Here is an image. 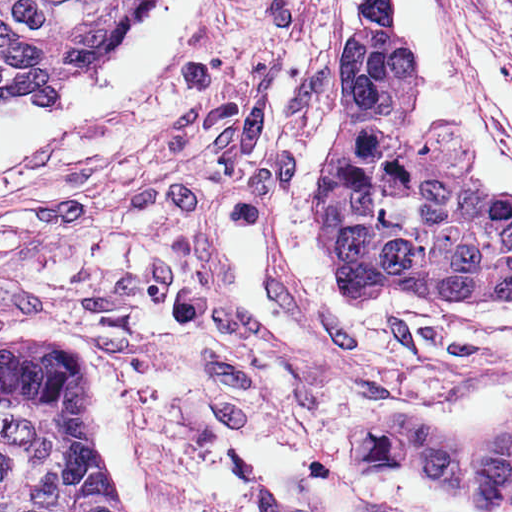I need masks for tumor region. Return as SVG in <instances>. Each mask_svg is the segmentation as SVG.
Returning a JSON list of instances; mask_svg holds the SVG:
<instances>
[{"label":"tumor region","mask_w":512,"mask_h":512,"mask_svg":"<svg viewBox=\"0 0 512 512\" xmlns=\"http://www.w3.org/2000/svg\"><path fill=\"white\" fill-rule=\"evenodd\" d=\"M151 0H0V115L65 91ZM395 0H362L333 84L315 239L346 295L418 304L512 299V198L476 179L459 143L421 136L401 98ZM414 453L474 497H512V431L469 448L428 424ZM0 512H129L100 464L88 357L68 345L0 351Z\"/></svg>","instance_id":"obj_1"}]
</instances>
